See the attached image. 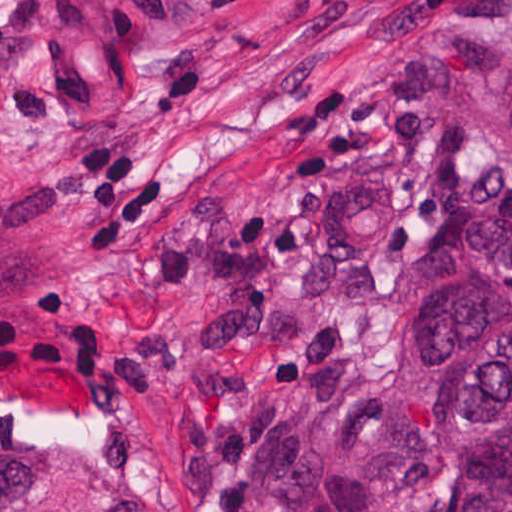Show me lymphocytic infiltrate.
Segmentation results:
<instances>
[{
    "mask_svg": "<svg viewBox=\"0 0 512 512\" xmlns=\"http://www.w3.org/2000/svg\"><path fill=\"white\" fill-rule=\"evenodd\" d=\"M422 117L421 102L404 74L381 88L328 90L285 119L289 143L331 142L299 152L291 159V173L299 188L320 186L335 173H350L361 182L371 178L365 167L369 155L392 147L410 153L418 167V185L408 206L411 228L447 222L470 187L462 176L468 154L465 127L424 126ZM70 182L88 211L77 235L83 244L137 240L172 212V187L161 175L135 189L120 140L82 148L70 168Z\"/></svg>",
    "mask_w": 512,
    "mask_h": 512,
    "instance_id": "1",
    "label": "lymphocytic infiltrate"
}]
</instances>
